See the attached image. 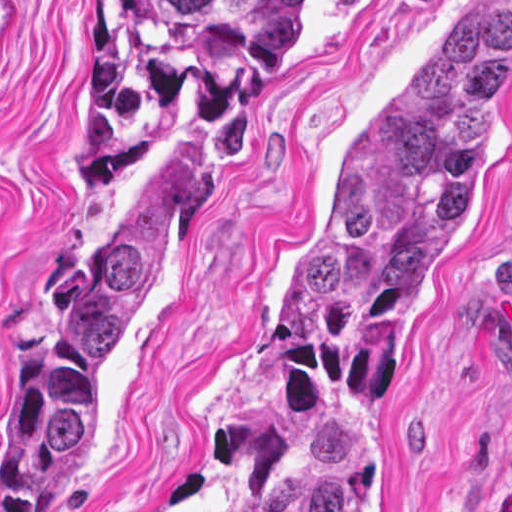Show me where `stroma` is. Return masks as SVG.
<instances>
[{"label":"stroma","mask_w":512,"mask_h":512,"mask_svg":"<svg viewBox=\"0 0 512 512\" xmlns=\"http://www.w3.org/2000/svg\"><path fill=\"white\" fill-rule=\"evenodd\" d=\"M476 1L298 4L98 450L36 512H228L205 441L222 403L255 380L283 270L391 78ZM494 1L512 25V0ZM99 76L100 0H0V498L34 455V356L47 328L157 185L194 98L86 200L72 164ZM361 512H512V114Z\"/></svg>","instance_id":"obj_1"}]
</instances>
